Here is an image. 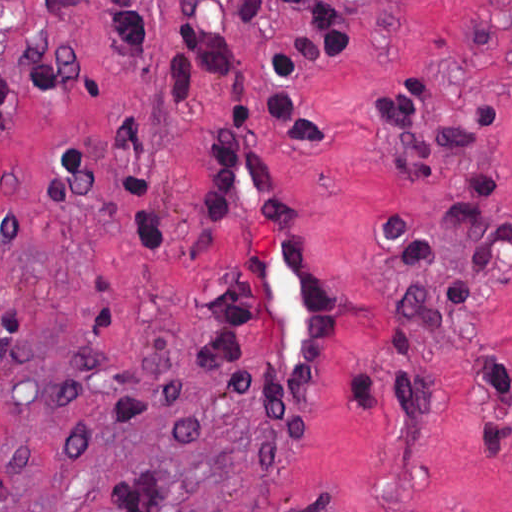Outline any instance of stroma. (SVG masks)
Returning a JSON list of instances; mask_svg holds the SVG:
<instances>
[{
	"instance_id": "1",
	"label": "stroma",
	"mask_w": 512,
	"mask_h": 512,
	"mask_svg": "<svg viewBox=\"0 0 512 512\" xmlns=\"http://www.w3.org/2000/svg\"><path fill=\"white\" fill-rule=\"evenodd\" d=\"M292 1L0 0V512H114L126 482L164 468L178 512H512V453L478 449L494 451L488 420L512 422L490 362L512 368V256L488 279L440 215L471 200L512 220V0H345L358 48L296 90L331 163L266 125ZM412 94L422 126L398 135L385 108ZM241 103L331 284L303 441L227 395L195 343L241 243V221L210 255L196 242L199 167ZM483 103L499 131L439 139L475 130ZM425 143L436 168L418 185L398 165ZM501 176L488 195L466 185ZM388 216L467 271L468 299L449 272L400 276L371 226ZM401 285L443 299L441 329L391 317ZM390 318L414 357L381 353ZM382 367L417 381L423 410L392 406Z\"/></svg>"
}]
</instances>
